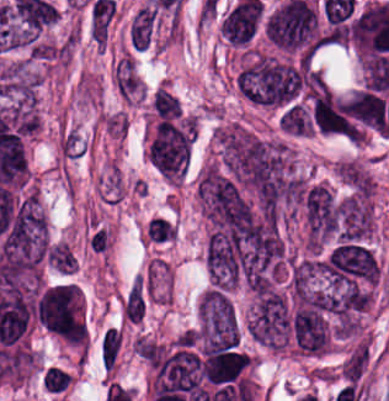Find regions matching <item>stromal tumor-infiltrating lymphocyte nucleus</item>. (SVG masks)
Returning <instances> with one entry per match:
<instances>
[{
    "label": "stromal tumor-infiltrating lymphocyte nucleus",
    "instance_id": "1",
    "mask_svg": "<svg viewBox=\"0 0 389 401\" xmlns=\"http://www.w3.org/2000/svg\"><path fill=\"white\" fill-rule=\"evenodd\" d=\"M146 241L166 243L176 238L174 224L166 216H152L145 225Z\"/></svg>",
    "mask_w": 389,
    "mask_h": 401
},
{
    "label": "stromal tumor-infiltrating lymphocyte nucleus",
    "instance_id": "2",
    "mask_svg": "<svg viewBox=\"0 0 389 401\" xmlns=\"http://www.w3.org/2000/svg\"><path fill=\"white\" fill-rule=\"evenodd\" d=\"M112 242L113 235L110 229L100 225H92L87 235V243L94 252L106 253L111 248Z\"/></svg>",
    "mask_w": 389,
    "mask_h": 401
}]
</instances>
